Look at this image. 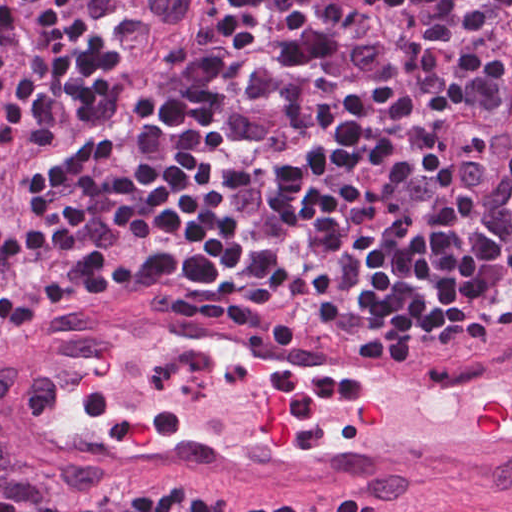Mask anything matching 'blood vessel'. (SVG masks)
<instances>
[{"label": "blood vessel", "instance_id": "8fb6f2fc", "mask_svg": "<svg viewBox=\"0 0 512 512\" xmlns=\"http://www.w3.org/2000/svg\"><path fill=\"white\" fill-rule=\"evenodd\" d=\"M459 323L244 327L119 294L43 330L0 395L65 475L512 491V296L444 342Z\"/></svg>", "mask_w": 512, "mask_h": 512}]
</instances>
